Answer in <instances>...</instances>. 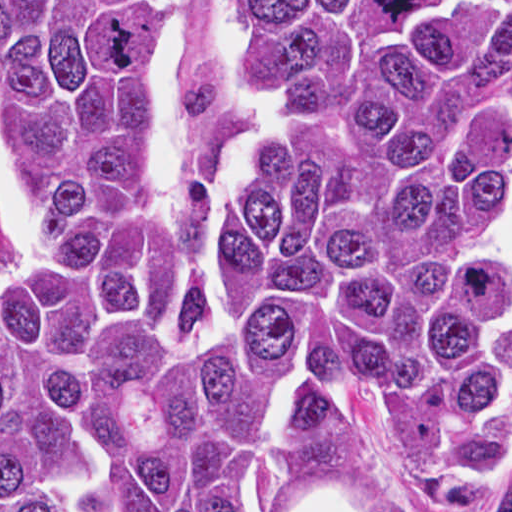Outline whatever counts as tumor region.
<instances>
[{
    "mask_svg": "<svg viewBox=\"0 0 512 512\" xmlns=\"http://www.w3.org/2000/svg\"><path fill=\"white\" fill-rule=\"evenodd\" d=\"M186 1H0V105L43 223L0 278V512H284L363 431L512 512V1H234L253 130L182 203ZM380 512H413L409 505Z\"/></svg>",
    "mask_w": 512,
    "mask_h": 512,
    "instance_id": "e687c5a6",
    "label": "tumor region"
}]
</instances>
